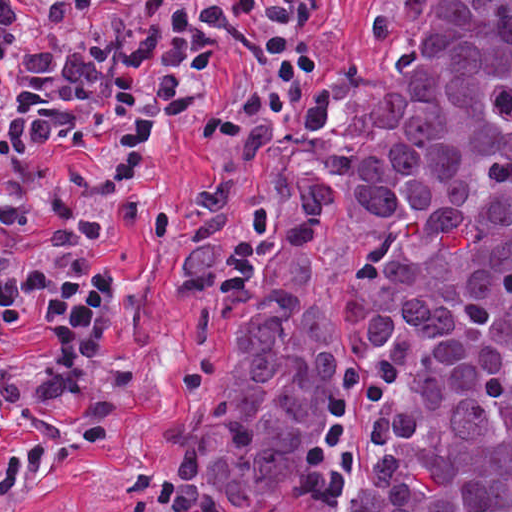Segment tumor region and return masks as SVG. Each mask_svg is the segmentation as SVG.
I'll use <instances>...</instances> for the list:
<instances>
[{
	"label": "tumor region",
	"mask_w": 512,
	"mask_h": 512,
	"mask_svg": "<svg viewBox=\"0 0 512 512\" xmlns=\"http://www.w3.org/2000/svg\"><path fill=\"white\" fill-rule=\"evenodd\" d=\"M174 265L227 305L189 512H512V0H392Z\"/></svg>",
	"instance_id": "obj_1"
}]
</instances>
